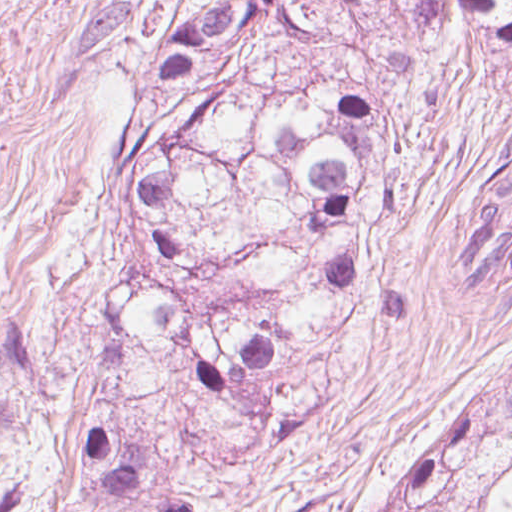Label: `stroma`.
<instances>
[{
  "instance_id": "1",
  "label": "stroma",
  "mask_w": 512,
  "mask_h": 512,
  "mask_svg": "<svg viewBox=\"0 0 512 512\" xmlns=\"http://www.w3.org/2000/svg\"><path fill=\"white\" fill-rule=\"evenodd\" d=\"M512 131V40L446 94L400 112L389 211L314 347L298 414L219 474L213 512H370L381 493L473 419V380L512 352V288L454 269L468 201ZM113 262L90 201L0 478V512H87L77 448L88 336Z\"/></svg>"
}]
</instances>
